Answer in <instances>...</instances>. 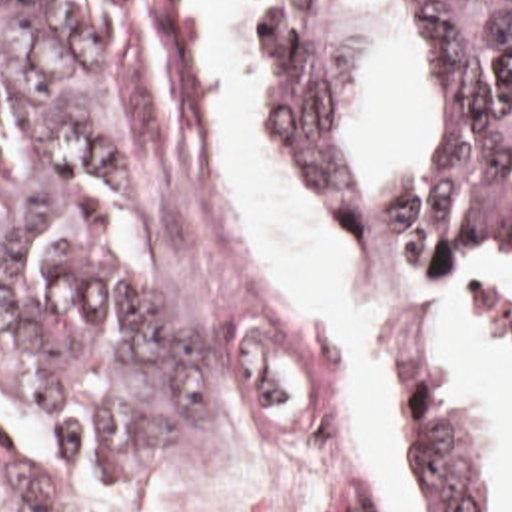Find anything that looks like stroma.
I'll return each mask as SVG.
<instances>
[{
    "label": "stroma",
    "instance_id": "obj_1",
    "mask_svg": "<svg viewBox=\"0 0 512 512\" xmlns=\"http://www.w3.org/2000/svg\"><path fill=\"white\" fill-rule=\"evenodd\" d=\"M235 9L247 53L253 123L287 195L317 239L345 265L369 277L424 289L468 307L490 325L512 359V281H460L391 265L373 255L371 213L379 197V175L373 171L365 215L343 227L327 211L289 147L279 113L277 75L265 51V25L253 1L235 0ZM121 21L135 115L153 149L167 201V235L193 281L195 303L215 345L213 445L231 425H259L307 447L321 445L337 419L339 399L331 323L305 305L257 255V223L229 177L213 119L209 75L183 0H121ZM417 337L409 335L405 341L397 389L407 373V351ZM422 337L438 343L454 369L474 419L500 461L512 501V455L504 435L440 337ZM395 417L397 395L381 475L383 505L343 512H403L393 483ZM0 431L25 475L63 512H139L197 467L137 481L111 495L119 501H103L1 399Z\"/></svg>",
    "mask_w": 512,
    "mask_h": 512
}]
</instances>
